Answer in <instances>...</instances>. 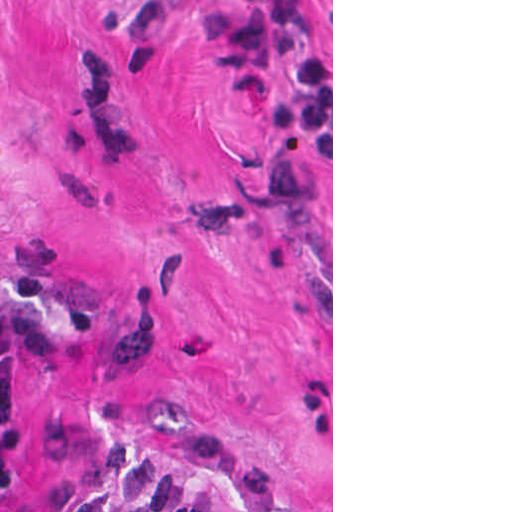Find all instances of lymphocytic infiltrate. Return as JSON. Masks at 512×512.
I'll list each match as a JSON object with an SVG mask.
<instances>
[{
    "label": "lymphocytic infiltrate",
    "mask_w": 512,
    "mask_h": 512,
    "mask_svg": "<svg viewBox=\"0 0 512 512\" xmlns=\"http://www.w3.org/2000/svg\"><path fill=\"white\" fill-rule=\"evenodd\" d=\"M71 349L68 321L51 305L0 291V485L33 442V396L48 361ZM0 512H223L194 481L137 446L72 454L26 499Z\"/></svg>",
    "instance_id": "obj_1"
}]
</instances>
